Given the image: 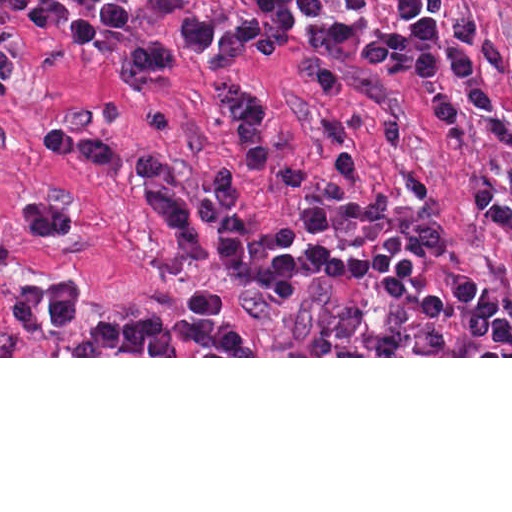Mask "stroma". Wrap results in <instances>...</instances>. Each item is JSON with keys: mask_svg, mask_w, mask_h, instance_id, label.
Wrapping results in <instances>:
<instances>
[{"mask_svg": "<svg viewBox=\"0 0 512 512\" xmlns=\"http://www.w3.org/2000/svg\"><path fill=\"white\" fill-rule=\"evenodd\" d=\"M119 1L131 19L125 25L100 22L90 55L71 43L67 24L36 30L25 10L0 6V35L26 69V84L0 81V306L12 292L48 276L72 277L81 290V317L69 329L21 334L0 317V358H512L483 328L461 320L460 306L447 293L450 273L466 269L503 295L512 311V244L473 208L477 192L512 167L477 138L461 143V137L438 131L414 85L378 77L365 66L377 40L411 38L394 19V0H364L357 9L329 0L323 16L301 12L288 35L274 31L246 0H231L282 48L330 61L359 80L357 98L338 104L260 57L238 64L236 77L272 96L280 150L312 166H330L332 137H348L373 190L392 196L384 221L333 237L308 235L266 178L238 201L212 200L226 215L285 223L298 232L305 299H277L190 258L134 186L151 183L172 197L187 193L183 189L109 180L90 166L45 153V139L69 129L211 170L239 161L220 93L200 60L186 61L134 96H123L120 88L127 53L139 44L182 43L187 17H209L206 2ZM459 6L481 18L512 57V0H461ZM436 21L439 30L441 19ZM486 78L512 123V85L498 73ZM27 190L64 197L74 214L68 236L31 239L10 223L11 201ZM397 231L423 247V264L408 290L438 295L437 318L415 324L409 306L374 295L373 274L321 277L306 264L311 242L361 259ZM202 289L220 294L221 320L255 336L257 356H71L83 328L142 316L186 317Z\"/></svg>", "mask_w": 512, "mask_h": 512, "instance_id": "stroma-1", "label": "stroma"}]
</instances>
